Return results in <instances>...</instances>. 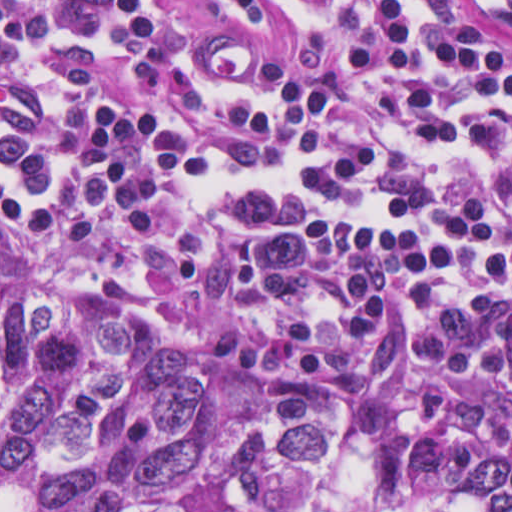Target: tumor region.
Wrapping results in <instances>:
<instances>
[{
	"label": "tumor region",
	"instance_id": "1",
	"mask_svg": "<svg viewBox=\"0 0 512 512\" xmlns=\"http://www.w3.org/2000/svg\"><path fill=\"white\" fill-rule=\"evenodd\" d=\"M344 427L324 386L0 280V512H229L227 492L316 487ZM351 512H512V463L403 451Z\"/></svg>",
	"mask_w": 512,
	"mask_h": 512
}]
</instances>
